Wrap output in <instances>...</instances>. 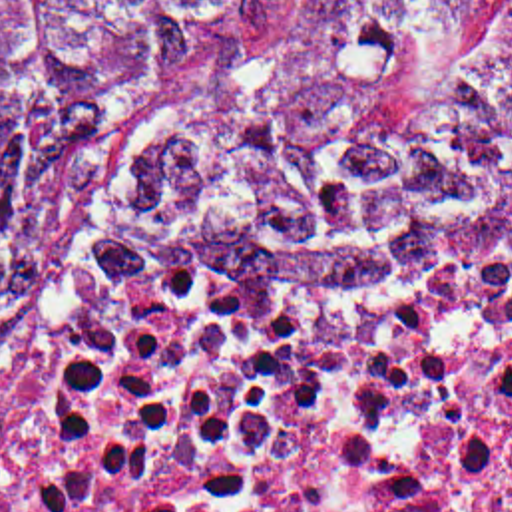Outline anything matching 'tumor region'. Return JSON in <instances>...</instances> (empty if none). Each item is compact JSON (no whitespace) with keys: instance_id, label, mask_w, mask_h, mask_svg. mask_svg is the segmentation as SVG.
<instances>
[{"instance_id":"tumor-region-1","label":"tumor region","mask_w":512,"mask_h":512,"mask_svg":"<svg viewBox=\"0 0 512 512\" xmlns=\"http://www.w3.org/2000/svg\"><path fill=\"white\" fill-rule=\"evenodd\" d=\"M289 0H0V400L30 382L111 169ZM125 215L239 293L412 297L512 271V0H314L161 141Z\"/></svg>"}]
</instances>
